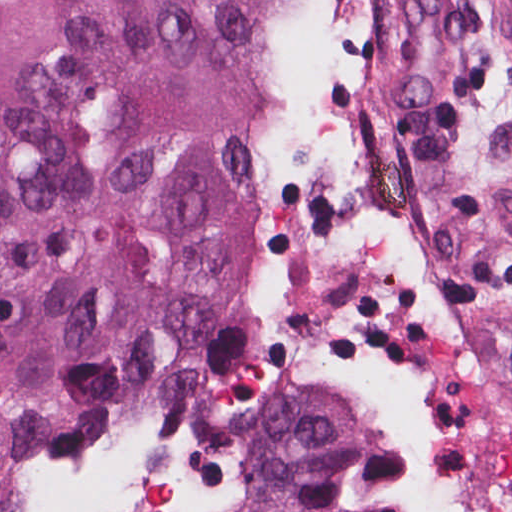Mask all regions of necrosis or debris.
Listing matches in <instances>:
<instances>
[{
    "mask_svg": "<svg viewBox=\"0 0 512 512\" xmlns=\"http://www.w3.org/2000/svg\"><path fill=\"white\" fill-rule=\"evenodd\" d=\"M333 0H302L275 132L252 192V252L208 342L173 359L108 434L111 512H246L298 406L385 408L402 477L451 509L471 493L465 353L430 265L409 165L350 122Z\"/></svg>",
    "mask_w": 512,
    "mask_h": 512,
    "instance_id": "obj_1",
    "label": "necrosis or debris"
}]
</instances>
